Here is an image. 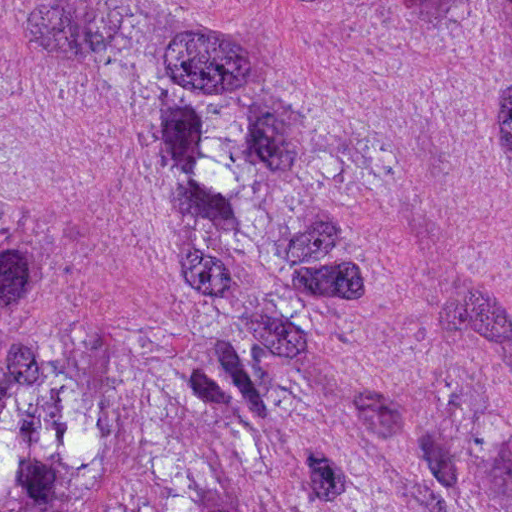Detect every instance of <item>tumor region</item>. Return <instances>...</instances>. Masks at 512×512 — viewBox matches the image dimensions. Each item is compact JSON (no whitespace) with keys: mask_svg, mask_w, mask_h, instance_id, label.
I'll return each mask as SVG.
<instances>
[{"mask_svg":"<svg viewBox=\"0 0 512 512\" xmlns=\"http://www.w3.org/2000/svg\"><path fill=\"white\" fill-rule=\"evenodd\" d=\"M0 512H512V0H0Z\"/></svg>","mask_w":512,"mask_h":512,"instance_id":"1","label":"tumor region"}]
</instances>
